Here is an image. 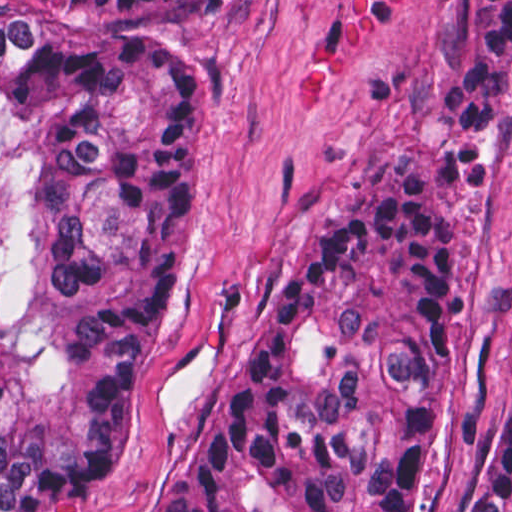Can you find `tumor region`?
<instances>
[{
  "mask_svg": "<svg viewBox=\"0 0 512 512\" xmlns=\"http://www.w3.org/2000/svg\"><path fill=\"white\" fill-rule=\"evenodd\" d=\"M218 1H0V512L121 473L179 289L204 114L172 30ZM512 1H473L441 92L491 190ZM452 344V201L366 184L272 292L144 512H411ZM462 512H512V389Z\"/></svg>",
  "mask_w": 512,
  "mask_h": 512,
  "instance_id": "e687c5a6",
  "label": "tumor region"
}]
</instances>
